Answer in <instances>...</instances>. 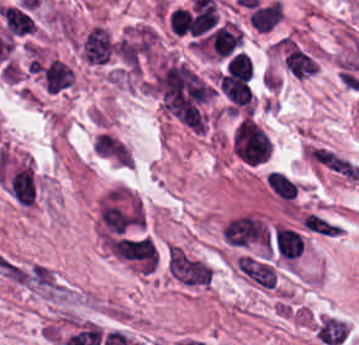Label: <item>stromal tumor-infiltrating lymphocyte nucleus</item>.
Instances as JSON below:
<instances>
[{
    "label": "stromal tumor-infiltrating lymphocyte nucleus",
    "mask_w": 359,
    "mask_h": 345,
    "mask_svg": "<svg viewBox=\"0 0 359 345\" xmlns=\"http://www.w3.org/2000/svg\"><path fill=\"white\" fill-rule=\"evenodd\" d=\"M80 54L91 64H105L115 54L116 44L110 32L100 25L86 30L78 42Z\"/></svg>",
    "instance_id": "52c7bb5b"
},
{
    "label": "stromal tumor-infiltrating lymphocyte nucleus",
    "mask_w": 359,
    "mask_h": 345,
    "mask_svg": "<svg viewBox=\"0 0 359 345\" xmlns=\"http://www.w3.org/2000/svg\"><path fill=\"white\" fill-rule=\"evenodd\" d=\"M280 17V5L274 0L253 9L248 20L259 32H268Z\"/></svg>",
    "instance_id": "abfb95fc"
},
{
    "label": "stromal tumor-infiltrating lymphocyte nucleus",
    "mask_w": 359,
    "mask_h": 345,
    "mask_svg": "<svg viewBox=\"0 0 359 345\" xmlns=\"http://www.w3.org/2000/svg\"><path fill=\"white\" fill-rule=\"evenodd\" d=\"M226 74L249 80L252 76V66L248 54L237 52L227 62Z\"/></svg>",
    "instance_id": "f3e2335f"
},
{
    "label": "stromal tumor-infiltrating lymphocyte nucleus",
    "mask_w": 359,
    "mask_h": 345,
    "mask_svg": "<svg viewBox=\"0 0 359 345\" xmlns=\"http://www.w3.org/2000/svg\"><path fill=\"white\" fill-rule=\"evenodd\" d=\"M168 29L174 34L185 36L191 32L190 9L182 6L172 7L168 16Z\"/></svg>",
    "instance_id": "9ea309e8"
},
{
    "label": "stromal tumor-infiltrating lymphocyte nucleus",
    "mask_w": 359,
    "mask_h": 345,
    "mask_svg": "<svg viewBox=\"0 0 359 345\" xmlns=\"http://www.w3.org/2000/svg\"><path fill=\"white\" fill-rule=\"evenodd\" d=\"M270 146L268 133L252 118L241 116L232 127L231 150L243 163H263Z\"/></svg>",
    "instance_id": "bc302bb0"
},
{
    "label": "stromal tumor-infiltrating lymphocyte nucleus",
    "mask_w": 359,
    "mask_h": 345,
    "mask_svg": "<svg viewBox=\"0 0 359 345\" xmlns=\"http://www.w3.org/2000/svg\"><path fill=\"white\" fill-rule=\"evenodd\" d=\"M44 90L56 92L73 82L70 67L60 59H52L42 71Z\"/></svg>",
    "instance_id": "3290ff9b"
}]
</instances>
